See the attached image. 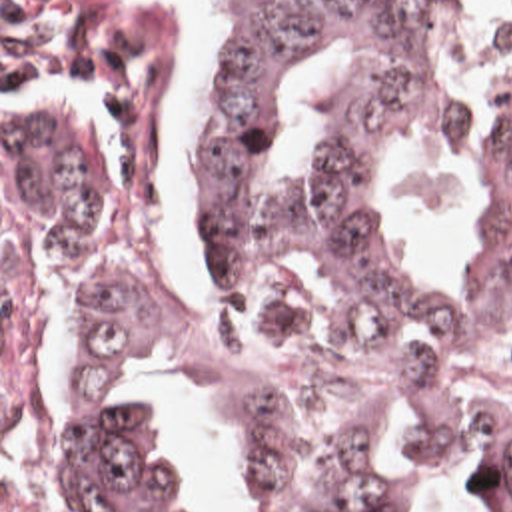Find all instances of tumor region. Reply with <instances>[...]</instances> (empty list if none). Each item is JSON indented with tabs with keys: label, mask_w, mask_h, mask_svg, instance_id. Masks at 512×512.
Wrapping results in <instances>:
<instances>
[{
	"label": "tumor region",
	"mask_w": 512,
	"mask_h": 512,
	"mask_svg": "<svg viewBox=\"0 0 512 512\" xmlns=\"http://www.w3.org/2000/svg\"><path fill=\"white\" fill-rule=\"evenodd\" d=\"M220 26L196 110V228L206 268L272 332L387 375L512 374V74L495 86L497 140L477 184L483 248L463 292H427L377 226L389 134L461 140L467 120L433 62L453 0H198ZM347 40L351 70L321 92L327 148L266 208L258 156L298 56ZM2 198L32 248H132L176 216L166 68L136 0H2ZM68 415L52 461L84 512H196L180 451L128 403V377L174 346L254 413L278 449L276 512H407L385 445L423 427L455 463L497 469L512 512V413L431 385L367 387L296 407L204 324L102 262L62 264Z\"/></svg>",
	"instance_id": "1"
}]
</instances>
